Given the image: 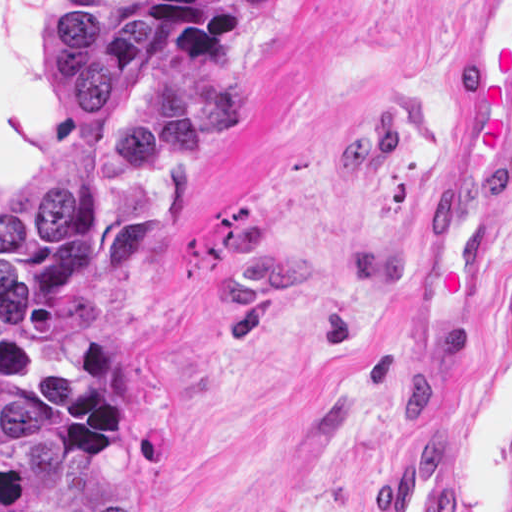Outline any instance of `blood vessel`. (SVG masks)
I'll return each instance as SVG.
<instances>
[{"instance_id": "1", "label": "blood vessel", "mask_w": 512, "mask_h": 512, "mask_svg": "<svg viewBox=\"0 0 512 512\" xmlns=\"http://www.w3.org/2000/svg\"><path fill=\"white\" fill-rule=\"evenodd\" d=\"M512 189V0H466L453 141L440 196L426 222L390 375L443 382L489 319L496 229ZM386 471L377 512H456V449L427 430Z\"/></svg>"}]
</instances>
